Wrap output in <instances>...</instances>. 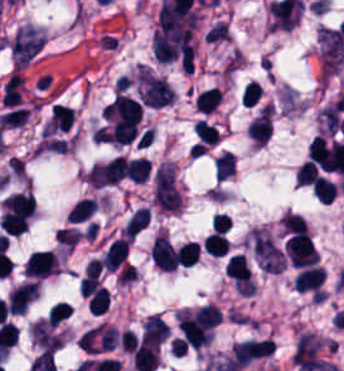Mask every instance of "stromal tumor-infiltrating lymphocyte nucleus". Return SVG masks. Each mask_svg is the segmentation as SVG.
I'll list each match as a JSON object with an SVG mask.
<instances>
[{"label":"stromal tumor-infiltrating lymphocyte nucleus","instance_id":"obj_1","mask_svg":"<svg viewBox=\"0 0 344 371\" xmlns=\"http://www.w3.org/2000/svg\"><path fill=\"white\" fill-rule=\"evenodd\" d=\"M58 270L56 255L53 251L34 250L23 265V274L46 277Z\"/></svg>","mask_w":344,"mask_h":371},{"label":"stromal tumor-infiltrating lymphocyte nucleus","instance_id":"obj_2","mask_svg":"<svg viewBox=\"0 0 344 371\" xmlns=\"http://www.w3.org/2000/svg\"><path fill=\"white\" fill-rule=\"evenodd\" d=\"M38 292L37 280H29L11 291L6 300L10 314H22L29 307Z\"/></svg>","mask_w":344,"mask_h":371},{"label":"stromal tumor-infiltrating lymphocyte nucleus","instance_id":"obj_3","mask_svg":"<svg viewBox=\"0 0 344 371\" xmlns=\"http://www.w3.org/2000/svg\"><path fill=\"white\" fill-rule=\"evenodd\" d=\"M325 279V270L323 266L310 265L303 266L296 279L298 291L320 293L322 291Z\"/></svg>","mask_w":344,"mask_h":371},{"label":"stromal tumor-infiltrating lymphocyte nucleus","instance_id":"obj_4","mask_svg":"<svg viewBox=\"0 0 344 371\" xmlns=\"http://www.w3.org/2000/svg\"><path fill=\"white\" fill-rule=\"evenodd\" d=\"M129 241L123 237H115L111 240L106 248L100 265L108 270H115L123 262Z\"/></svg>","mask_w":344,"mask_h":371},{"label":"stromal tumor-infiltrating lymphocyte nucleus","instance_id":"obj_5","mask_svg":"<svg viewBox=\"0 0 344 371\" xmlns=\"http://www.w3.org/2000/svg\"><path fill=\"white\" fill-rule=\"evenodd\" d=\"M132 359L138 371H152L159 361L157 345L140 343L134 347Z\"/></svg>","mask_w":344,"mask_h":371},{"label":"stromal tumor-infiltrating lymphocyte nucleus","instance_id":"obj_6","mask_svg":"<svg viewBox=\"0 0 344 371\" xmlns=\"http://www.w3.org/2000/svg\"><path fill=\"white\" fill-rule=\"evenodd\" d=\"M271 126L269 110H262L247 126V133L255 145H264L269 137Z\"/></svg>","mask_w":344,"mask_h":371},{"label":"stromal tumor-infiltrating lymphocyte nucleus","instance_id":"obj_7","mask_svg":"<svg viewBox=\"0 0 344 371\" xmlns=\"http://www.w3.org/2000/svg\"><path fill=\"white\" fill-rule=\"evenodd\" d=\"M168 328L157 313H149L143 322L142 338L147 342L158 344L164 338Z\"/></svg>","mask_w":344,"mask_h":371},{"label":"stromal tumor-infiltrating lymphocyte nucleus","instance_id":"obj_8","mask_svg":"<svg viewBox=\"0 0 344 371\" xmlns=\"http://www.w3.org/2000/svg\"><path fill=\"white\" fill-rule=\"evenodd\" d=\"M149 218L148 206L137 208L125 222L123 233L134 240L148 225Z\"/></svg>","mask_w":344,"mask_h":371},{"label":"stromal tumor-infiltrating lymphocyte nucleus","instance_id":"obj_9","mask_svg":"<svg viewBox=\"0 0 344 371\" xmlns=\"http://www.w3.org/2000/svg\"><path fill=\"white\" fill-rule=\"evenodd\" d=\"M200 242L187 241L176 253V264L180 266H192L196 264L200 256Z\"/></svg>","mask_w":344,"mask_h":371},{"label":"stromal tumor-infiltrating lymphocyte nucleus","instance_id":"obj_10","mask_svg":"<svg viewBox=\"0 0 344 371\" xmlns=\"http://www.w3.org/2000/svg\"><path fill=\"white\" fill-rule=\"evenodd\" d=\"M221 98V88L212 86L196 96L195 103L197 110L208 113L219 104Z\"/></svg>","mask_w":344,"mask_h":371},{"label":"stromal tumor-infiltrating lymphocyte nucleus","instance_id":"obj_11","mask_svg":"<svg viewBox=\"0 0 344 371\" xmlns=\"http://www.w3.org/2000/svg\"><path fill=\"white\" fill-rule=\"evenodd\" d=\"M204 250L212 255H225L229 244L224 232H210L202 244Z\"/></svg>","mask_w":344,"mask_h":371},{"label":"stromal tumor-infiltrating lymphocyte nucleus","instance_id":"obj_12","mask_svg":"<svg viewBox=\"0 0 344 371\" xmlns=\"http://www.w3.org/2000/svg\"><path fill=\"white\" fill-rule=\"evenodd\" d=\"M96 205L94 198L81 197L71 206L67 218L77 222L86 219L95 211Z\"/></svg>","mask_w":344,"mask_h":371},{"label":"stromal tumor-infiltrating lymphocyte nucleus","instance_id":"obj_13","mask_svg":"<svg viewBox=\"0 0 344 371\" xmlns=\"http://www.w3.org/2000/svg\"><path fill=\"white\" fill-rule=\"evenodd\" d=\"M196 322L207 326H216L221 317V309L216 304H202L194 314Z\"/></svg>","mask_w":344,"mask_h":371},{"label":"stromal tumor-infiltrating lymphocyte nucleus","instance_id":"obj_14","mask_svg":"<svg viewBox=\"0 0 344 371\" xmlns=\"http://www.w3.org/2000/svg\"><path fill=\"white\" fill-rule=\"evenodd\" d=\"M151 167L149 159L145 157L128 160V175L137 182H144L150 175Z\"/></svg>","mask_w":344,"mask_h":371},{"label":"stromal tumor-infiltrating lymphocyte nucleus","instance_id":"obj_15","mask_svg":"<svg viewBox=\"0 0 344 371\" xmlns=\"http://www.w3.org/2000/svg\"><path fill=\"white\" fill-rule=\"evenodd\" d=\"M194 129L202 142L216 144L221 137L216 125L202 117L195 121Z\"/></svg>","mask_w":344,"mask_h":371},{"label":"stromal tumor-infiltrating lymphocyte nucleus","instance_id":"obj_16","mask_svg":"<svg viewBox=\"0 0 344 371\" xmlns=\"http://www.w3.org/2000/svg\"><path fill=\"white\" fill-rule=\"evenodd\" d=\"M234 168L235 160L231 150H224L214 160L215 178L225 179Z\"/></svg>","mask_w":344,"mask_h":371},{"label":"stromal tumor-infiltrating lymphocyte nucleus","instance_id":"obj_17","mask_svg":"<svg viewBox=\"0 0 344 371\" xmlns=\"http://www.w3.org/2000/svg\"><path fill=\"white\" fill-rule=\"evenodd\" d=\"M72 304L63 301L53 302L47 320L55 326L71 314Z\"/></svg>","mask_w":344,"mask_h":371},{"label":"stromal tumor-infiltrating lymphocyte nucleus","instance_id":"obj_18","mask_svg":"<svg viewBox=\"0 0 344 371\" xmlns=\"http://www.w3.org/2000/svg\"><path fill=\"white\" fill-rule=\"evenodd\" d=\"M314 192L324 202H331L335 195V184L326 178L319 177L314 183Z\"/></svg>","mask_w":344,"mask_h":371},{"label":"stromal tumor-infiltrating lymphocyte nucleus","instance_id":"obj_19","mask_svg":"<svg viewBox=\"0 0 344 371\" xmlns=\"http://www.w3.org/2000/svg\"><path fill=\"white\" fill-rule=\"evenodd\" d=\"M109 303V293L102 285L88 299L89 309L101 313Z\"/></svg>","mask_w":344,"mask_h":371},{"label":"stromal tumor-infiltrating lymphocyte nucleus","instance_id":"obj_20","mask_svg":"<svg viewBox=\"0 0 344 371\" xmlns=\"http://www.w3.org/2000/svg\"><path fill=\"white\" fill-rule=\"evenodd\" d=\"M263 94V90L258 81H251L247 85L244 86L243 89V105L248 106H255L261 96Z\"/></svg>","mask_w":344,"mask_h":371},{"label":"stromal tumor-infiltrating lymphocyte nucleus","instance_id":"obj_21","mask_svg":"<svg viewBox=\"0 0 344 371\" xmlns=\"http://www.w3.org/2000/svg\"><path fill=\"white\" fill-rule=\"evenodd\" d=\"M283 228L288 232H297L306 230L307 224L303 217L293 212H285L282 216Z\"/></svg>","mask_w":344,"mask_h":371},{"label":"stromal tumor-infiltrating lymphocyte nucleus","instance_id":"obj_22","mask_svg":"<svg viewBox=\"0 0 344 371\" xmlns=\"http://www.w3.org/2000/svg\"><path fill=\"white\" fill-rule=\"evenodd\" d=\"M317 168L308 161H304L296 170L295 178L300 184L312 183L317 177Z\"/></svg>","mask_w":344,"mask_h":371}]
</instances>
